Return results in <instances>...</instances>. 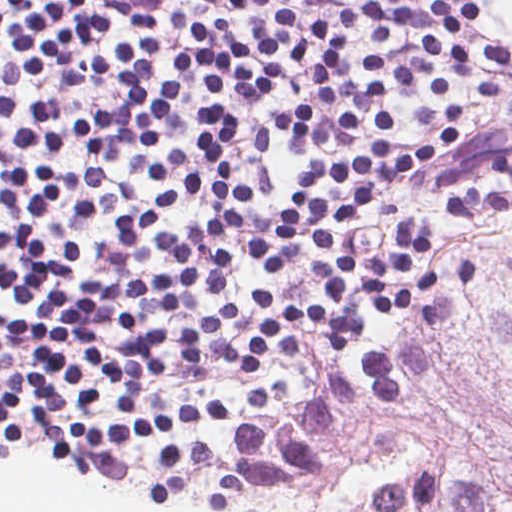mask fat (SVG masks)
Listing matches in <instances>:
<instances>
[{"instance_id":"fat-1","label":"fat","mask_w":512,"mask_h":512,"mask_svg":"<svg viewBox=\"0 0 512 512\" xmlns=\"http://www.w3.org/2000/svg\"><path fill=\"white\" fill-rule=\"evenodd\" d=\"M488 27L512 40V0H495Z\"/></svg>"}]
</instances>
